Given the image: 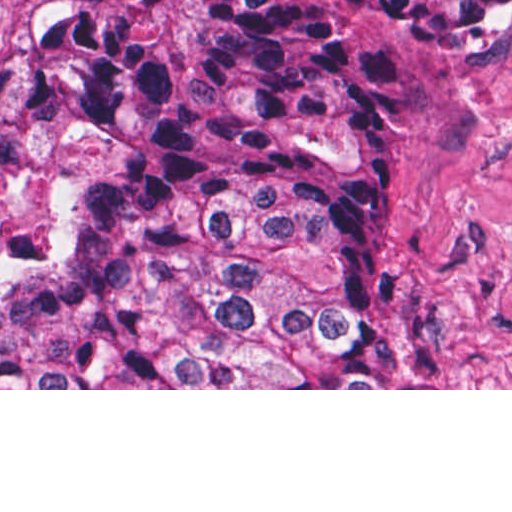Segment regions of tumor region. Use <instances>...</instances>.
<instances>
[{"mask_svg":"<svg viewBox=\"0 0 512 512\" xmlns=\"http://www.w3.org/2000/svg\"><path fill=\"white\" fill-rule=\"evenodd\" d=\"M198 0L184 58L124 20L22 26L45 106L107 163L60 262L0 301V388H418L378 317L399 65L512 48V0Z\"/></svg>","mask_w":512,"mask_h":512,"instance_id":"obj_1","label":"tumor region"}]
</instances>
